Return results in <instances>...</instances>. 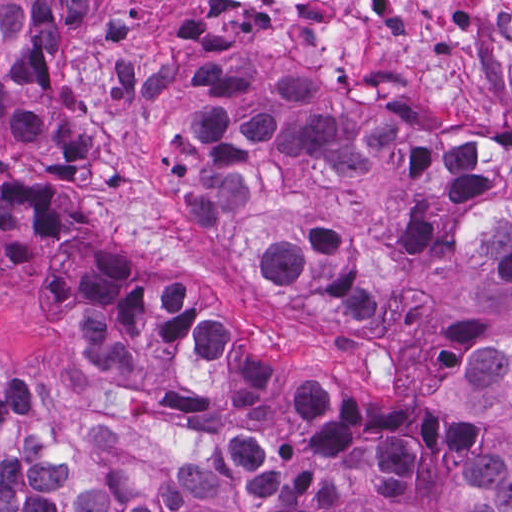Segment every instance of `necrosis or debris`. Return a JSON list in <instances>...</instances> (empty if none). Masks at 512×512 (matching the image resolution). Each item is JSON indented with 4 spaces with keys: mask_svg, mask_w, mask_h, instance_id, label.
Masks as SVG:
<instances>
[{
    "mask_svg": "<svg viewBox=\"0 0 512 512\" xmlns=\"http://www.w3.org/2000/svg\"><path fill=\"white\" fill-rule=\"evenodd\" d=\"M280 27L283 62L378 98L431 131L512 144V0H228Z\"/></svg>",
    "mask_w": 512,
    "mask_h": 512,
    "instance_id": "obj_1",
    "label": "necrosis or debris"
}]
</instances>
